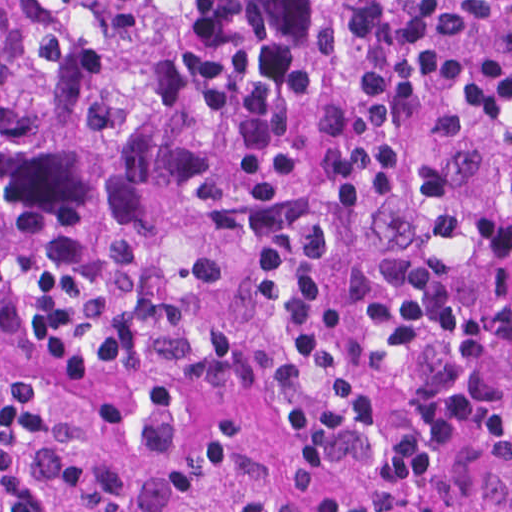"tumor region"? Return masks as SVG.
I'll return each mask as SVG.
<instances>
[{
    "instance_id": "obj_1",
    "label": "tumor region",
    "mask_w": 512,
    "mask_h": 512,
    "mask_svg": "<svg viewBox=\"0 0 512 512\" xmlns=\"http://www.w3.org/2000/svg\"><path fill=\"white\" fill-rule=\"evenodd\" d=\"M511 180L512 0H0V512H221L231 407Z\"/></svg>"
}]
</instances>
